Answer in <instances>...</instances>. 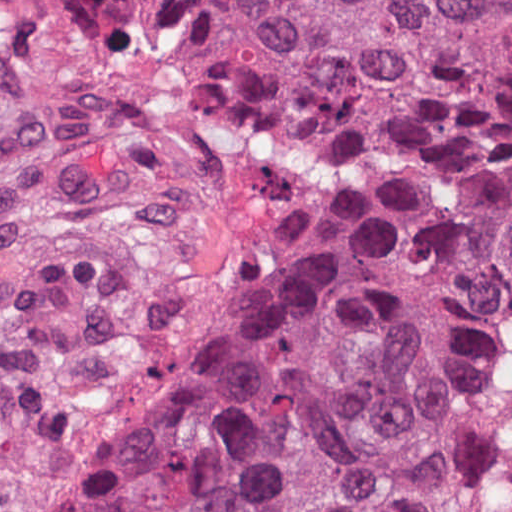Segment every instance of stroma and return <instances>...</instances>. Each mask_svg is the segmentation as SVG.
<instances>
[{
  "label": "stroma",
  "instance_id": "obj_1",
  "mask_svg": "<svg viewBox=\"0 0 512 512\" xmlns=\"http://www.w3.org/2000/svg\"><path fill=\"white\" fill-rule=\"evenodd\" d=\"M370 203V146L218 36L83 47L0 0V512H88L222 319Z\"/></svg>",
  "mask_w": 512,
  "mask_h": 512
}]
</instances>
